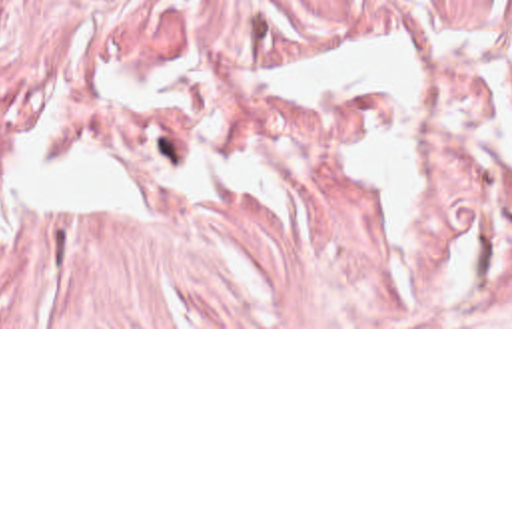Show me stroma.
<instances>
[{"label":"stroma","mask_w":512,"mask_h":512,"mask_svg":"<svg viewBox=\"0 0 512 512\" xmlns=\"http://www.w3.org/2000/svg\"><path fill=\"white\" fill-rule=\"evenodd\" d=\"M426 51L424 247L344 189L364 101L257 113L233 139L282 181L195 195L169 117L107 79L193 51L253 87L241 48ZM0 145L89 151L149 219H0V329H512V8L500 0H0Z\"/></svg>","instance_id":"35a3bbf8"}]
</instances>
